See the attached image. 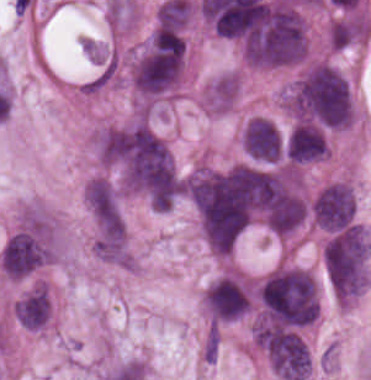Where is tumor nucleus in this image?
Returning <instances> with one entry per match:
<instances>
[{"label": "tumor nucleus", "instance_id": "obj_4", "mask_svg": "<svg viewBox=\"0 0 371 380\" xmlns=\"http://www.w3.org/2000/svg\"><path fill=\"white\" fill-rule=\"evenodd\" d=\"M356 215L355 193L350 184L331 182L321 188L312 204L315 225L328 232L353 225Z\"/></svg>", "mask_w": 371, "mask_h": 380}, {"label": "tumor nucleus", "instance_id": "obj_6", "mask_svg": "<svg viewBox=\"0 0 371 380\" xmlns=\"http://www.w3.org/2000/svg\"><path fill=\"white\" fill-rule=\"evenodd\" d=\"M283 153L289 164H303L329 156L326 131L314 120L302 119L288 131Z\"/></svg>", "mask_w": 371, "mask_h": 380}, {"label": "tumor nucleus", "instance_id": "obj_5", "mask_svg": "<svg viewBox=\"0 0 371 380\" xmlns=\"http://www.w3.org/2000/svg\"><path fill=\"white\" fill-rule=\"evenodd\" d=\"M54 254L47 241L13 234L1 251L2 273L9 279H23L51 262Z\"/></svg>", "mask_w": 371, "mask_h": 380}, {"label": "tumor nucleus", "instance_id": "obj_9", "mask_svg": "<svg viewBox=\"0 0 371 380\" xmlns=\"http://www.w3.org/2000/svg\"><path fill=\"white\" fill-rule=\"evenodd\" d=\"M328 41L339 51L362 41L361 16L350 14L334 20L329 27Z\"/></svg>", "mask_w": 371, "mask_h": 380}, {"label": "tumor nucleus", "instance_id": "obj_8", "mask_svg": "<svg viewBox=\"0 0 371 380\" xmlns=\"http://www.w3.org/2000/svg\"><path fill=\"white\" fill-rule=\"evenodd\" d=\"M241 81L232 72L221 73L204 90V101L210 112L224 113L231 109L239 94Z\"/></svg>", "mask_w": 371, "mask_h": 380}, {"label": "tumor nucleus", "instance_id": "obj_7", "mask_svg": "<svg viewBox=\"0 0 371 380\" xmlns=\"http://www.w3.org/2000/svg\"><path fill=\"white\" fill-rule=\"evenodd\" d=\"M13 311L20 325L28 329L37 331L45 327L52 316V306L44 284L27 290L13 304Z\"/></svg>", "mask_w": 371, "mask_h": 380}, {"label": "tumor nucleus", "instance_id": "obj_1", "mask_svg": "<svg viewBox=\"0 0 371 380\" xmlns=\"http://www.w3.org/2000/svg\"><path fill=\"white\" fill-rule=\"evenodd\" d=\"M306 50L302 16L285 0H266L247 20L241 57L247 65L272 68L300 61Z\"/></svg>", "mask_w": 371, "mask_h": 380}, {"label": "tumor nucleus", "instance_id": "obj_3", "mask_svg": "<svg viewBox=\"0 0 371 380\" xmlns=\"http://www.w3.org/2000/svg\"><path fill=\"white\" fill-rule=\"evenodd\" d=\"M202 303L210 325L245 317L250 309V282L235 273L218 277L204 289Z\"/></svg>", "mask_w": 371, "mask_h": 380}, {"label": "tumor nucleus", "instance_id": "obj_2", "mask_svg": "<svg viewBox=\"0 0 371 380\" xmlns=\"http://www.w3.org/2000/svg\"><path fill=\"white\" fill-rule=\"evenodd\" d=\"M326 277L340 302L349 303L365 288L371 266V238L364 227L333 232L323 249Z\"/></svg>", "mask_w": 371, "mask_h": 380}]
</instances>
